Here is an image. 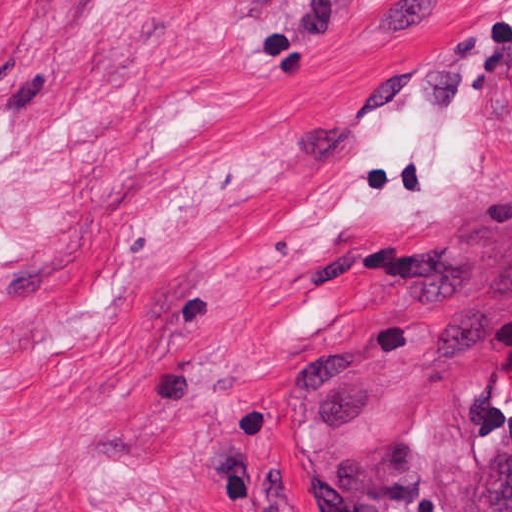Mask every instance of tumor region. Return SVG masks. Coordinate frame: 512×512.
<instances>
[{"label":"tumor region","mask_w":512,"mask_h":512,"mask_svg":"<svg viewBox=\"0 0 512 512\" xmlns=\"http://www.w3.org/2000/svg\"><path fill=\"white\" fill-rule=\"evenodd\" d=\"M453 512H512V447L491 458L476 488Z\"/></svg>","instance_id":"e687c5a6"}]
</instances>
